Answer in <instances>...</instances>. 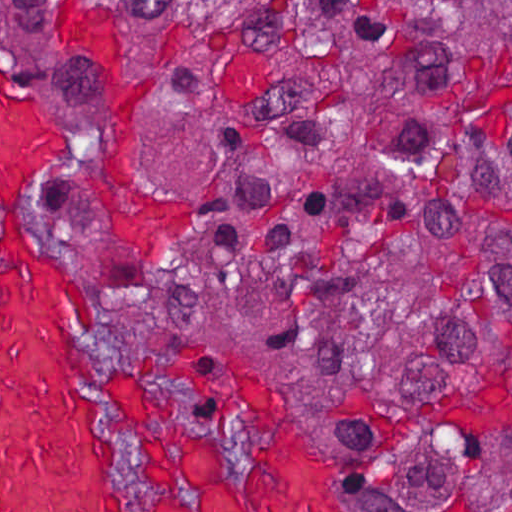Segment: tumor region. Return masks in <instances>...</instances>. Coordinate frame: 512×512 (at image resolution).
Here are the masks:
<instances>
[{
	"label": "tumor region",
	"mask_w": 512,
	"mask_h": 512,
	"mask_svg": "<svg viewBox=\"0 0 512 512\" xmlns=\"http://www.w3.org/2000/svg\"><path fill=\"white\" fill-rule=\"evenodd\" d=\"M114 165L189 174L130 298L278 350L405 512H512V1H0Z\"/></svg>",
	"instance_id": "obj_1"
}]
</instances>
